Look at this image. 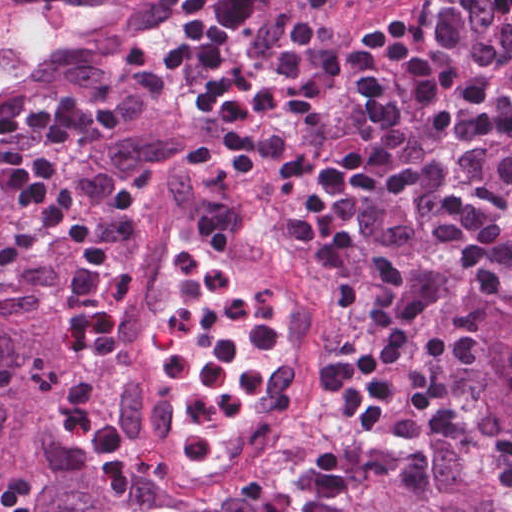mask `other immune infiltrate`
Masks as SVG:
<instances>
[{
  "instance_id": "bc1004c8",
  "label": "other immune infiltrate",
  "mask_w": 512,
  "mask_h": 512,
  "mask_svg": "<svg viewBox=\"0 0 512 512\" xmlns=\"http://www.w3.org/2000/svg\"><path fill=\"white\" fill-rule=\"evenodd\" d=\"M222 259H224V258H222ZM226 262L228 264H230L228 261H226ZM230 265L234 269H236L241 275H243L247 280L254 283L255 285L262 288L263 290H265L266 292H268L269 294H271L272 296H274L276 298L275 292L268 284L255 278L250 273L243 271L240 268H238L232 264H230ZM173 302H174V283L171 278V275L169 274L167 291L162 295L160 301L152 308L151 313L149 314V316L147 317V319L145 321L148 344H149L150 359L152 357V346H153L154 338H155L156 334L158 333V331L160 330L161 326L163 325L166 317L168 316L170 309L173 305ZM152 370H153V368H152ZM274 370H275V365H273V367L269 373V376L266 380L267 386H269V383L271 381ZM153 372L157 376V373L154 370H153Z\"/></svg>"
}]
</instances>
